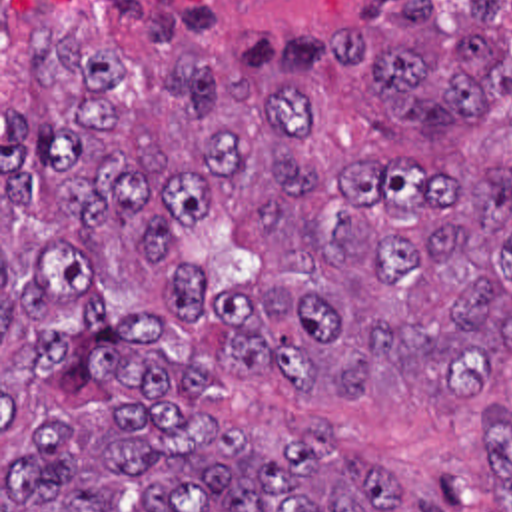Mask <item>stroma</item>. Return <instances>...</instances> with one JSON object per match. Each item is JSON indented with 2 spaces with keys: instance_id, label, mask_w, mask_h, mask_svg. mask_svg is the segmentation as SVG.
<instances>
[{
  "instance_id": "35a3bbf8",
  "label": "stroma",
  "mask_w": 512,
  "mask_h": 512,
  "mask_svg": "<svg viewBox=\"0 0 512 512\" xmlns=\"http://www.w3.org/2000/svg\"><path fill=\"white\" fill-rule=\"evenodd\" d=\"M357 0H0V512L2 453L20 449L18 428L88 410L102 402L160 404L118 384H94L82 394H52L22 380L8 354L42 330L78 332L86 312L58 304L48 318L10 316L2 330V260L16 280L28 276L44 250H68L92 270L106 320L160 318L162 354L186 358L212 374V388L192 414L240 424L278 447L313 424L361 447L393 479L433 497L443 512H511L497 495L493 451L485 432L491 408L512 406V372L493 390L477 424L457 420L443 404H365L341 400L325 410L303 406L286 382L254 368L242 378L226 368L236 344L232 314L220 292L238 280H266L270 252L246 222L214 220L180 228L202 280L194 310L170 308L160 280L128 250L118 228L82 230L62 222L52 182L28 210L2 206V108L52 128L78 98V82L38 80L30 58L56 34L102 46L120 64L112 96H146L156 58L202 60L246 86L299 80L319 100L343 160H405L447 180H471L487 170L512 172V88L491 94L477 122H393L375 100L373 74L345 66L335 54V28L355 16ZM437 20L455 32L493 42L512 68V0H435ZM509 76H512L509 74ZM12 512H26L24 509Z\"/></svg>"
}]
</instances>
